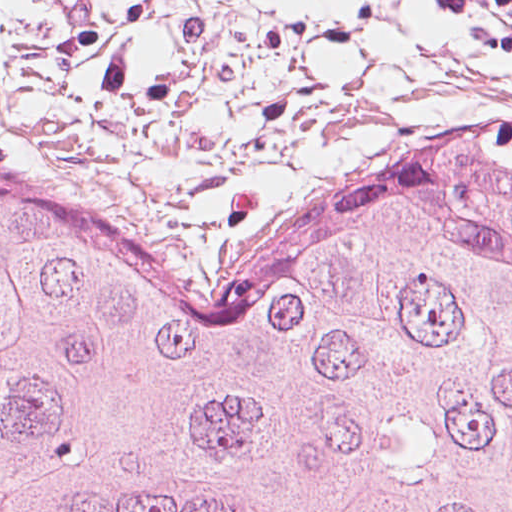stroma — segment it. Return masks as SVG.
Listing matches in <instances>:
<instances>
[{"label":"stroma","mask_w":512,"mask_h":512,"mask_svg":"<svg viewBox=\"0 0 512 512\" xmlns=\"http://www.w3.org/2000/svg\"><path fill=\"white\" fill-rule=\"evenodd\" d=\"M0 171L44 185L140 253L235 279L345 211L0 138Z\"/></svg>","instance_id":"obj_1"}]
</instances>
